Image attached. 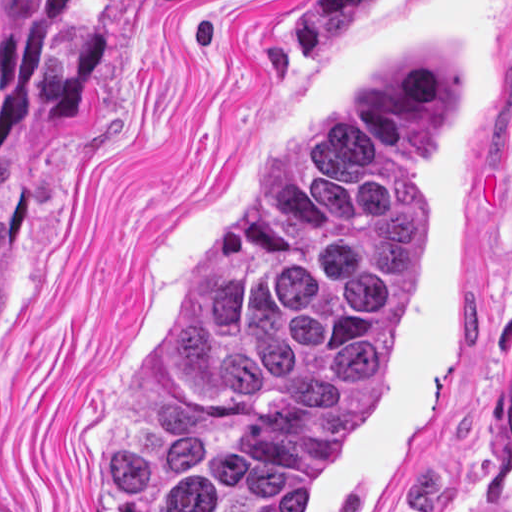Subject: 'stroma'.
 Listing matches in <instances>:
<instances>
[{
	"label": "stroma",
	"instance_id": "35a3bbf8",
	"mask_svg": "<svg viewBox=\"0 0 512 512\" xmlns=\"http://www.w3.org/2000/svg\"><path fill=\"white\" fill-rule=\"evenodd\" d=\"M300 0H0V512H100V431L227 235L389 67L466 46L439 264L391 392L303 512H512V0H388L336 68Z\"/></svg>",
	"mask_w": 512,
	"mask_h": 512
}]
</instances>
